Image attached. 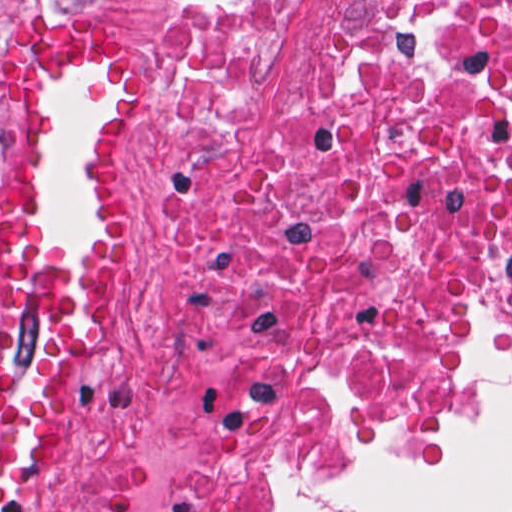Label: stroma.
Wrapping results in <instances>:
<instances>
[{
    "mask_svg": "<svg viewBox=\"0 0 512 512\" xmlns=\"http://www.w3.org/2000/svg\"><path fill=\"white\" fill-rule=\"evenodd\" d=\"M187 0H0V41L34 21H76L131 48L138 67L131 84L112 93L100 79H57L40 89L29 125V198L40 251L57 265H92L84 207V157L113 100L132 103L118 138V178L136 228L118 282V303L105 340L78 365L75 442L67 459L26 498L22 512H68L95 455L101 385L128 366L139 409L168 356L171 312L157 246V175L178 125V14ZM355 0H274L269 22V80L277 99L294 81L313 43ZM6 152L0 127V200ZM504 368L512 363L487 361ZM501 371L483 362L458 412L433 441L387 463L349 470H285L232 480L259 490L263 512H289V491L358 483L400 471L440 469L443 451L480 431L495 412Z\"/></svg>",
    "mask_w": 512,
    "mask_h": 512,
    "instance_id": "obj_1",
    "label": "stroma"
}]
</instances>
